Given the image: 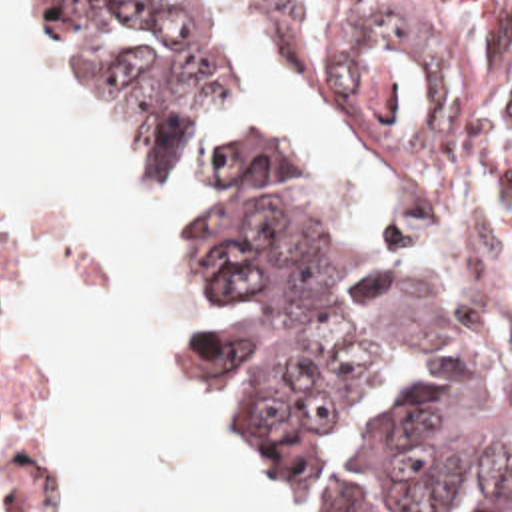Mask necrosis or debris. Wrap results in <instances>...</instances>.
<instances>
[{
	"instance_id": "1",
	"label": "necrosis or debris",
	"mask_w": 512,
	"mask_h": 512,
	"mask_svg": "<svg viewBox=\"0 0 512 512\" xmlns=\"http://www.w3.org/2000/svg\"><path fill=\"white\" fill-rule=\"evenodd\" d=\"M382 176L446 226L512 318V0H276ZM1 240V234H0ZM0 475L23 512L49 481L0 375Z\"/></svg>"
}]
</instances>
